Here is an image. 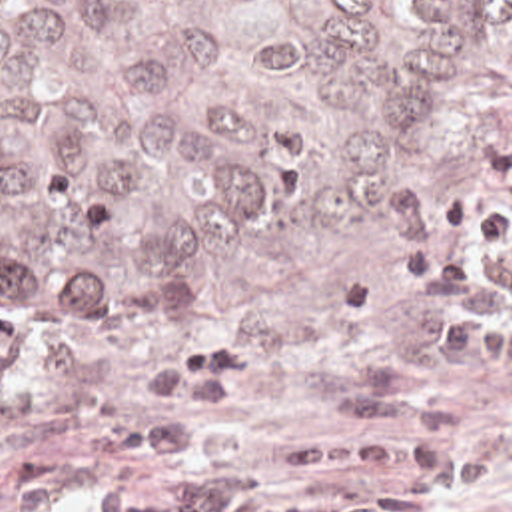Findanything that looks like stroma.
<instances>
[{
    "label": "stroma",
    "instance_id": "35a3bbf8",
    "mask_svg": "<svg viewBox=\"0 0 512 512\" xmlns=\"http://www.w3.org/2000/svg\"><path fill=\"white\" fill-rule=\"evenodd\" d=\"M511 93L512 33L393 253L317 303L249 319L0 309V512H52L68 497L85 512L89 491L143 477L151 463L135 449V423L163 401L147 393L143 369L191 347H241L253 359L245 385L199 439L215 475L273 473L327 445L407 433L449 353L429 347L403 305L401 261L485 153ZM453 413L483 433L489 475L435 507L512 512V367L481 371Z\"/></svg>",
    "mask_w": 512,
    "mask_h": 512
}]
</instances>
